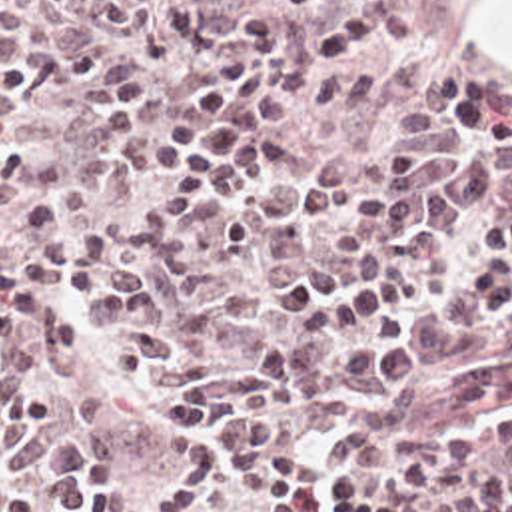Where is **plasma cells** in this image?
I'll return each mask as SVG.
<instances>
[{
	"mask_svg": "<svg viewBox=\"0 0 512 512\" xmlns=\"http://www.w3.org/2000/svg\"><path fill=\"white\" fill-rule=\"evenodd\" d=\"M0 512H512L460 11L0 0Z\"/></svg>",
	"mask_w": 512,
	"mask_h": 512,
	"instance_id": "9512152a",
	"label": "plasma cells"
}]
</instances>
